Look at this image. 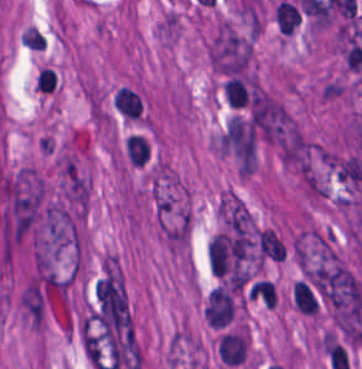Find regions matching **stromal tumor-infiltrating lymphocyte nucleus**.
I'll return each instance as SVG.
<instances>
[{
  "label": "stromal tumor-infiltrating lymphocyte nucleus",
  "mask_w": 362,
  "mask_h": 369,
  "mask_svg": "<svg viewBox=\"0 0 362 369\" xmlns=\"http://www.w3.org/2000/svg\"><path fill=\"white\" fill-rule=\"evenodd\" d=\"M234 312L230 292L224 286H216L209 294L205 317L211 327H222Z\"/></svg>",
  "instance_id": "bc302bb0"
},
{
  "label": "stromal tumor-infiltrating lymphocyte nucleus",
  "mask_w": 362,
  "mask_h": 369,
  "mask_svg": "<svg viewBox=\"0 0 362 369\" xmlns=\"http://www.w3.org/2000/svg\"><path fill=\"white\" fill-rule=\"evenodd\" d=\"M113 104L125 118L137 119L142 109V98L133 87L120 86L113 93Z\"/></svg>",
  "instance_id": "52c7bb5b"
},
{
  "label": "stromal tumor-infiltrating lymphocyte nucleus",
  "mask_w": 362,
  "mask_h": 369,
  "mask_svg": "<svg viewBox=\"0 0 362 369\" xmlns=\"http://www.w3.org/2000/svg\"><path fill=\"white\" fill-rule=\"evenodd\" d=\"M293 303L305 314H316L317 297L306 281L296 280L292 289Z\"/></svg>",
  "instance_id": "3290ff9b"
},
{
  "label": "stromal tumor-infiltrating lymphocyte nucleus",
  "mask_w": 362,
  "mask_h": 369,
  "mask_svg": "<svg viewBox=\"0 0 362 369\" xmlns=\"http://www.w3.org/2000/svg\"><path fill=\"white\" fill-rule=\"evenodd\" d=\"M126 152L132 162L143 165L149 157L146 139L137 133H129L126 138Z\"/></svg>",
  "instance_id": "abfb95fc"
},
{
  "label": "stromal tumor-infiltrating lymphocyte nucleus",
  "mask_w": 362,
  "mask_h": 369,
  "mask_svg": "<svg viewBox=\"0 0 362 369\" xmlns=\"http://www.w3.org/2000/svg\"><path fill=\"white\" fill-rule=\"evenodd\" d=\"M250 296L266 307H275L277 294L275 284L270 280H262L251 286Z\"/></svg>",
  "instance_id": "9ea309e8"
},
{
  "label": "stromal tumor-infiltrating lymphocyte nucleus",
  "mask_w": 362,
  "mask_h": 369,
  "mask_svg": "<svg viewBox=\"0 0 362 369\" xmlns=\"http://www.w3.org/2000/svg\"><path fill=\"white\" fill-rule=\"evenodd\" d=\"M56 85V72L48 67H41L35 79L39 91L52 92Z\"/></svg>",
  "instance_id": "f3e2335f"
},
{
  "label": "stromal tumor-infiltrating lymphocyte nucleus",
  "mask_w": 362,
  "mask_h": 369,
  "mask_svg": "<svg viewBox=\"0 0 362 369\" xmlns=\"http://www.w3.org/2000/svg\"><path fill=\"white\" fill-rule=\"evenodd\" d=\"M21 40L30 50H44V36L32 25L21 35Z\"/></svg>",
  "instance_id": "4f13568d"
}]
</instances>
